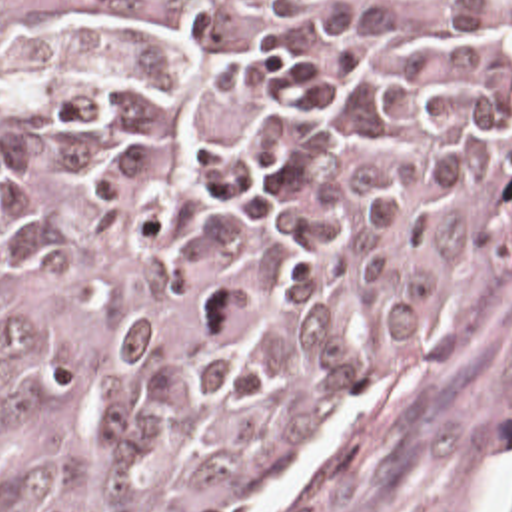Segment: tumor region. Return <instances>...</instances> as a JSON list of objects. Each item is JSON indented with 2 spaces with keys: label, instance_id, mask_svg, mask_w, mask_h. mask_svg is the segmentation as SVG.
I'll return each instance as SVG.
<instances>
[{
  "label": "tumor region",
  "instance_id": "e687c5a6",
  "mask_svg": "<svg viewBox=\"0 0 512 512\" xmlns=\"http://www.w3.org/2000/svg\"><path fill=\"white\" fill-rule=\"evenodd\" d=\"M510 190L512 0H0V512L279 491Z\"/></svg>",
  "mask_w": 512,
  "mask_h": 512
}]
</instances>
